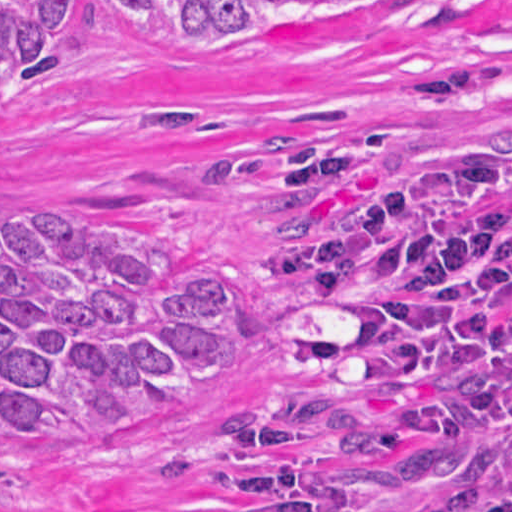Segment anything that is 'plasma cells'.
<instances>
[{"mask_svg": "<svg viewBox=\"0 0 512 512\" xmlns=\"http://www.w3.org/2000/svg\"><path fill=\"white\" fill-rule=\"evenodd\" d=\"M277 271L298 292L359 309L408 352L512 357V170L493 144L421 154L338 201L286 192ZM471 512H512V454Z\"/></svg>", "mask_w": 512, "mask_h": 512, "instance_id": "plasma-cells-1", "label": "plasma cells"}]
</instances>
